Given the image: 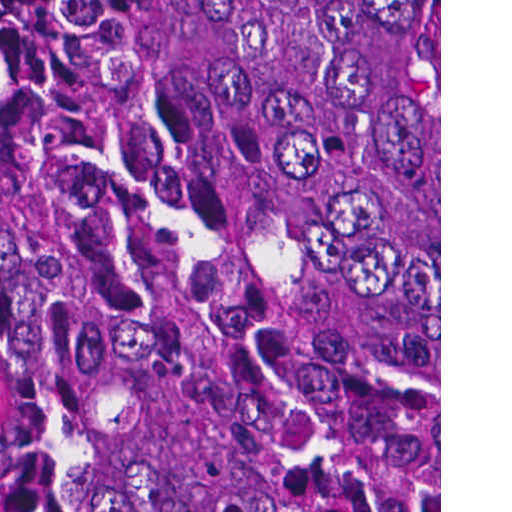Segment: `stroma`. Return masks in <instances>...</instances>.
<instances>
[{
	"instance_id": "obj_1",
	"label": "stroma",
	"mask_w": 512,
	"mask_h": 512,
	"mask_svg": "<svg viewBox=\"0 0 512 512\" xmlns=\"http://www.w3.org/2000/svg\"><path fill=\"white\" fill-rule=\"evenodd\" d=\"M0 512H34L25 478L11 363L1 314ZM439 512H441V0H439Z\"/></svg>"
}]
</instances>
